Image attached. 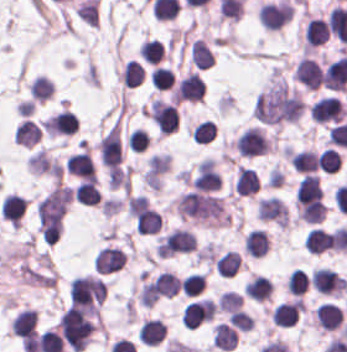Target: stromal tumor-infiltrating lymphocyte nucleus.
I'll return each mask as SVG.
<instances>
[{"label": "stromal tumor-infiltrating lymphocyte nucleus", "instance_id": "stromal-tumor-infiltrating-lymphocyte-nucleus-1", "mask_svg": "<svg viewBox=\"0 0 347 352\" xmlns=\"http://www.w3.org/2000/svg\"><path fill=\"white\" fill-rule=\"evenodd\" d=\"M60 335L72 352H78L89 342L95 325L89 315L68 306L57 321Z\"/></svg>", "mask_w": 347, "mask_h": 352}, {"label": "stromal tumor-infiltrating lymphocyte nucleus", "instance_id": "stromal-tumor-infiltrating-lymphocyte-nucleus-2", "mask_svg": "<svg viewBox=\"0 0 347 352\" xmlns=\"http://www.w3.org/2000/svg\"><path fill=\"white\" fill-rule=\"evenodd\" d=\"M104 300L103 279L93 274H79L69 282L71 305L91 314L98 315Z\"/></svg>", "mask_w": 347, "mask_h": 352}, {"label": "stromal tumor-infiltrating lymphocyte nucleus", "instance_id": "stromal-tumor-infiltrating-lymphocyte-nucleus-3", "mask_svg": "<svg viewBox=\"0 0 347 352\" xmlns=\"http://www.w3.org/2000/svg\"><path fill=\"white\" fill-rule=\"evenodd\" d=\"M233 145L238 152L250 158L268 153L270 139L263 128L253 124L236 136Z\"/></svg>", "mask_w": 347, "mask_h": 352}, {"label": "stromal tumor-infiltrating lymphocyte nucleus", "instance_id": "stromal-tumor-infiltrating-lymphocyte-nucleus-4", "mask_svg": "<svg viewBox=\"0 0 347 352\" xmlns=\"http://www.w3.org/2000/svg\"><path fill=\"white\" fill-rule=\"evenodd\" d=\"M292 13L291 4L278 0L259 4L257 20L264 30H278L287 23Z\"/></svg>", "mask_w": 347, "mask_h": 352}, {"label": "stromal tumor-infiltrating lymphocyte nucleus", "instance_id": "stromal-tumor-infiltrating-lymphocyte-nucleus-5", "mask_svg": "<svg viewBox=\"0 0 347 352\" xmlns=\"http://www.w3.org/2000/svg\"><path fill=\"white\" fill-rule=\"evenodd\" d=\"M312 122H338L344 118L347 110L335 96H321L313 100L308 107Z\"/></svg>", "mask_w": 347, "mask_h": 352}, {"label": "stromal tumor-infiltrating lymphocyte nucleus", "instance_id": "stromal-tumor-infiltrating-lymphocyte-nucleus-6", "mask_svg": "<svg viewBox=\"0 0 347 352\" xmlns=\"http://www.w3.org/2000/svg\"><path fill=\"white\" fill-rule=\"evenodd\" d=\"M204 95V85L196 71H188L176 84L175 102H199Z\"/></svg>", "mask_w": 347, "mask_h": 352}, {"label": "stromal tumor-infiltrating lymphocyte nucleus", "instance_id": "stromal-tumor-infiltrating-lymphocyte-nucleus-7", "mask_svg": "<svg viewBox=\"0 0 347 352\" xmlns=\"http://www.w3.org/2000/svg\"><path fill=\"white\" fill-rule=\"evenodd\" d=\"M255 212L260 220L287 224L289 214L282 200L276 196H263L257 199Z\"/></svg>", "mask_w": 347, "mask_h": 352}, {"label": "stromal tumor-infiltrating lymphocyte nucleus", "instance_id": "stromal-tumor-infiltrating-lymphocyte-nucleus-8", "mask_svg": "<svg viewBox=\"0 0 347 352\" xmlns=\"http://www.w3.org/2000/svg\"><path fill=\"white\" fill-rule=\"evenodd\" d=\"M126 258L125 252L116 246L104 245L98 248L92 263L94 270L99 273H108L122 266Z\"/></svg>", "mask_w": 347, "mask_h": 352}, {"label": "stromal tumor-infiltrating lymphocyte nucleus", "instance_id": "stromal-tumor-infiltrating-lymphocyte-nucleus-9", "mask_svg": "<svg viewBox=\"0 0 347 352\" xmlns=\"http://www.w3.org/2000/svg\"><path fill=\"white\" fill-rule=\"evenodd\" d=\"M67 172L82 179H95V167L89 152L78 150L67 155L64 162Z\"/></svg>", "mask_w": 347, "mask_h": 352}, {"label": "stromal tumor-infiltrating lymphocyte nucleus", "instance_id": "stromal-tumor-infiltrating-lymphocyte-nucleus-10", "mask_svg": "<svg viewBox=\"0 0 347 352\" xmlns=\"http://www.w3.org/2000/svg\"><path fill=\"white\" fill-rule=\"evenodd\" d=\"M321 66L309 56H301L297 62L293 75L296 80L309 89H317L320 76Z\"/></svg>", "mask_w": 347, "mask_h": 352}, {"label": "stromal tumor-infiltrating lymphocyte nucleus", "instance_id": "stromal-tumor-infiltrating-lymphocyte-nucleus-11", "mask_svg": "<svg viewBox=\"0 0 347 352\" xmlns=\"http://www.w3.org/2000/svg\"><path fill=\"white\" fill-rule=\"evenodd\" d=\"M300 309L301 300L299 298L281 300L274 305L270 319L275 326H291L297 321Z\"/></svg>", "mask_w": 347, "mask_h": 352}, {"label": "stromal tumor-infiltrating lymphocyte nucleus", "instance_id": "stromal-tumor-infiltrating-lymphocyte-nucleus-12", "mask_svg": "<svg viewBox=\"0 0 347 352\" xmlns=\"http://www.w3.org/2000/svg\"><path fill=\"white\" fill-rule=\"evenodd\" d=\"M328 35L327 21L317 16H310L303 32L304 48L322 45Z\"/></svg>", "mask_w": 347, "mask_h": 352}, {"label": "stromal tumor-infiltrating lymphocyte nucleus", "instance_id": "stromal-tumor-infiltrating-lymphocyte-nucleus-13", "mask_svg": "<svg viewBox=\"0 0 347 352\" xmlns=\"http://www.w3.org/2000/svg\"><path fill=\"white\" fill-rule=\"evenodd\" d=\"M27 201L20 194L6 192L1 204V217L12 223H20Z\"/></svg>", "mask_w": 347, "mask_h": 352}, {"label": "stromal tumor-infiltrating lymphocyte nucleus", "instance_id": "stromal-tumor-infiltrating-lymphocyte-nucleus-14", "mask_svg": "<svg viewBox=\"0 0 347 352\" xmlns=\"http://www.w3.org/2000/svg\"><path fill=\"white\" fill-rule=\"evenodd\" d=\"M41 138V130L36 122L23 118L15 126L12 134V141L27 147H32Z\"/></svg>", "mask_w": 347, "mask_h": 352}, {"label": "stromal tumor-infiltrating lymphocyte nucleus", "instance_id": "stromal-tumor-infiltrating-lymphocyte-nucleus-15", "mask_svg": "<svg viewBox=\"0 0 347 352\" xmlns=\"http://www.w3.org/2000/svg\"><path fill=\"white\" fill-rule=\"evenodd\" d=\"M268 247V235L259 228L249 230L243 239V248L249 257H263Z\"/></svg>", "mask_w": 347, "mask_h": 352}, {"label": "stromal tumor-infiltrating lymphocyte nucleus", "instance_id": "stromal-tumor-infiltrating-lymphocyte-nucleus-16", "mask_svg": "<svg viewBox=\"0 0 347 352\" xmlns=\"http://www.w3.org/2000/svg\"><path fill=\"white\" fill-rule=\"evenodd\" d=\"M288 162L296 172H313L317 153L311 149H289Z\"/></svg>", "mask_w": 347, "mask_h": 352}, {"label": "stromal tumor-infiltrating lymphocyte nucleus", "instance_id": "stromal-tumor-infiltrating-lymphocyte-nucleus-17", "mask_svg": "<svg viewBox=\"0 0 347 352\" xmlns=\"http://www.w3.org/2000/svg\"><path fill=\"white\" fill-rule=\"evenodd\" d=\"M258 187V175L251 169L240 166L237 169L232 185L236 195H249Z\"/></svg>", "mask_w": 347, "mask_h": 352}, {"label": "stromal tumor-infiltrating lymphocyte nucleus", "instance_id": "stromal-tumor-infiltrating-lymphocyte-nucleus-18", "mask_svg": "<svg viewBox=\"0 0 347 352\" xmlns=\"http://www.w3.org/2000/svg\"><path fill=\"white\" fill-rule=\"evenodd\" d=\"M188 60L192 65L200 68L211 67L214 58L206 43L199 37L192 40L188 49Z\"/></svg>", "mask_w": 347, "mask_h": 352}, {"label": "stromal tumor-infiltrating lymphocyte nucleus", "instance_id": "stromal-tumor-infiltrating-lymphocyte-nucleus-19", "mask_svg": "<svg viewBox=\"0 0 347 352\" xmlns=\"http://www.w3.org/2000/svg\"><path fill=\"white\" fill-rule=\"evenodd\" d=\"M330 244V237L326 230L318 227H311L303 240V248L311 254H320L327 251Z\"/></svg>", "mask_w": 347, "mask_h": 352}, {"label": "stromal tumor-infiltrating lymphocyte nucleus", "instance_id": "stromal-tumor-infiltrating-lymphocyte-nucleus-20", "mask_svg": "<svg viewBox=\"0 0 347 352\" xmlns=\"http://www.w3.org/2000/svg\"><path fill=\"white\" fill-rule=\"evenodd\" d=\"M36 323V314L32 309L22 308L19 309L10 321L9 327L12 334L23 335L33 331Z\"/></svg>", "mask_w": 347, "mask_h": 352}, {"label": "stromal tumor-infiltrating lymphocyte nucleus", "instance_id": "stromal-tumor-infiltrating-lymphocyte-nucleus-21", "mask_svg": "<svg viewBox=\"0 0 347 352\" xmlns=\"http://www.w3.org/2000/svg\"><path fill=\"white\" fill-rule=\"evenodd\" d=\"M73 200L88 204L95 205L99 202L100 194L94 181L81 180L72 189Z\"/></svg>", "mask_w": 347, "mask_h": 352}, {"label": "stromal tumor-infiltrating lymphocyte nucleus", "instance_id": "stromal-tumor-infiltrating-lymphocyte-nucleus-22", "mask_svg": "<svg viewBox=\"0 0 347 352\" xmlns=\"http://www.w3.org/2000/svg\"><path fill=\"white\" fill-rule=\"evenodd\" d=\"M120 77L125 88H132L144 79V72L139 61L128 59L120 68Z\"/></svg>", "mask_w": 347, "mask_h": 352}, {"label": "stromal tumor-infiltrating lymphocyte nucleus", "instance_id": "stromal-tumor-infiltrating-lymphocyte-nucleus-23", "mask_svg": "<svg viewBox=\"0 0 347 352\" xmlns=\"http://www.w3.org/2000/svg\"><path fill=\"white\" fill-rule=\"evenodd\" d=\"M53 88H54V84L51 78L43 75H36L33 81L28 86L27 90L32 100H37L42 102L52 97Z\"/></svg>", "mask_w": 347, "mask_h": 352}, {"label": "stromal tumor-infiltrating lymphocyte nucleus", "instance_id": "stromal-tumor-infiltrating-lymphocyte-nucleus-24", "mask_svg": "<svg viewBox=\"0 0 347 352\" xmlns=\"http://www.w3.org/2000/svg\"><path fill=\"white\" fill-rule=\"evenodd\" d=\"M239 262V253L228 250L215 259V269L222 277H233L237 273Z\"/></svg>", "mask_w": 347, "mask_h": 352}, {"label": "stromal tumor-infiltrating lymphocyte nucleus", "instance_id": "stromal-tumor-infiltrating-lymphocyte-nucleus-25", "mask_svg": "<svg viewBox=\"0 0 347 352\" xmlns=\"http://www.w3.org/2000/svg\"><path fill=\"white\" fill-rule=\"evenodd\" d=\"M138 52L143 60L155 65L163 58L162 45L154 37H146L140 42Z\"/></svg>", "mask_w": 347, "mask_h": 352}, {"label": "stromal tumor-infiltrating lymphocyte nucleus", "instance_id": "stromal-tumor-infiltrating-lymphocyte-nucleus-26", "mask_svg": "<svg viewBox=\"0 0 347 352\" xmlns=\"http://www.w3.org/2000/svg\"><path fill=\"white\" fill-rule=\"evenodd\" d=\"M286 290L291 295H301L309 285V278L300 268H293L286 274Z\"/></svg>", "mask_w": 347, "mask_h": 352}, {"label": "stromal tumor-infiltrating lymphocyte nucleus", "instance_id": "stromal-tumor-infiltrating-lymphocyte-nucleus-27", "mask_svg": "<svg viewBox=\"0 0 347 352\" xmlns=\"http://www.w3.org/2000/svg\"><path fill=\"white\" fill-rule=\"evenodd\" d=\"M174 78L173 71L162 65H155L149 72L150 83L161 91L173 86Z\"/></svg>", "mask_w": 347, "mask_h": 352}, {"label": "stromal tumor-infiltrating lymphocyte nucleus", "instance_id": "stromal-tumor-infiltrating-lymphocyte-nucleus-28", "mask_svg": "<svg viewBox=\"0 0 347 352\" xmlns=\"http://www.w3.org/2000/svg\"><path fill=\"white\" fill-rule=\"evenodd\" d=\"M188 134L195 143H208L214 135V123L206 118L196 123Z\"/></svg>", "mask_w": 347, "mask_h": 352}, {"label": "stromal tumor-infiltrating lymphocyte nucleus", "instance_id": "stromal-tumor-infiltrating-lymphocyte-nucleus-29", "mask_svg": "<svg viewBox=\"0 0 347 352\" xmlns=\"http://www.w3.org/2000/svg\"><path fill=\"white\" fill-rule=\"evenodd\" d=\"M243 300L242 294L232 290L224 289L217 297L218 308L221 311L231 312L239 309Z\"/></svg>", "mask_w": 347, "mask_h": 352}, {"label": "stromal tumor-infiltrating lymphocyte nucleus", "instance_id": "stromal-tumor-infiltrating-lymphocyte-nucleus-30", "mask_svg": "<svg viewBox=\"0 0 347 352\" xmlns=\"http://www.w3.org/2000/svg\"><path fill=\"white\" fill-rule=\"evenodd\" d=\"M341 163V155L333 148H326L317 158V165L322 172H336Z\"/></svg>", "mask_w": 347, "mask_h": 352}, {"label": "stromal tumor-infiltrating lymphocyte nucleus", "instance_id": "stromal-tumor-infiltrating-lymphocyte-nucleus-31", "mask_svg": "<svg viewBox=\"0 0 347 352\" xmlns=\"http://www.w3.org/2000/svg\"><path fill=\"white\" fill-rule=\"evenodd\" d=\"M184 295H197L203 289V272H190L181 278Z\"/></svg>", "mask_w": 347, "mask_h": 352}, {"label": "stromal tumor-infiltrating lymphocyte nucleus", "instance_id": "stromal-tumor-infiltrating-lymphocyte-nucleus-32", "mask_svg": "<svg viewBox=\"0 0 347 352\" xmlns=\"http://www.w3.org/2000/svg\"><path fill=\"white\" fill-rule=\"evenodd\" d=\"M228 320L231 325L241 331H249L252 328L254 322V319L240 308L229 312Z\"/></svg>", "mask_w": 347, "mask_h": 352}]
</instances>
